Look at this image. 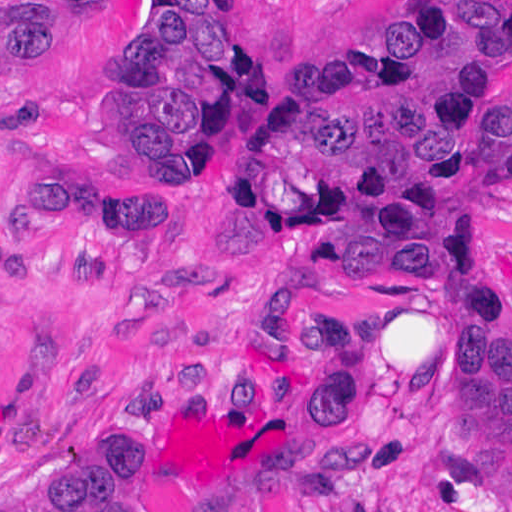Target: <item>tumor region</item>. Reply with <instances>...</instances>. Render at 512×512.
<instances>
[{
	"instance_id": "tumor-region-1",
	"label": "tumor region",
	"mask_w": 512,
	"mask_h": 512,
	"mask_svg": "<svg viewBox=\"0 0 512 512\" xmlns=\"http://www.w3.org/2000/svg\"><path fill=\"white\" fill-rule=\"evenodd\" d=\"M100 0H0V90L24 81L42 41L72 9ZM138 32L100 89L114 139L139 166L195 185L193 170L248 62L218 0H143ZM512 34V0H418L364 48L305 60L262 118L236 195L347 218L385 231L437 300L458 378V450L512 464V284L437 242L445 214L512 189V98L476 79V52ZM179 207H144L74 178L24 169L5 220L16 239L68 240L72 275L104 283L134 232L181 234ZM4 226V229H5ZM339 276H386L335 247ZM34 287L36 264L0 228V277ZM360 326L316 318L299 365L255 369L318 415L314 456L262 479L246 512H340L372 452L347 429V372ZM10 512H178L158 466L136 442Z\"/></svg>"
}]
</instances>
